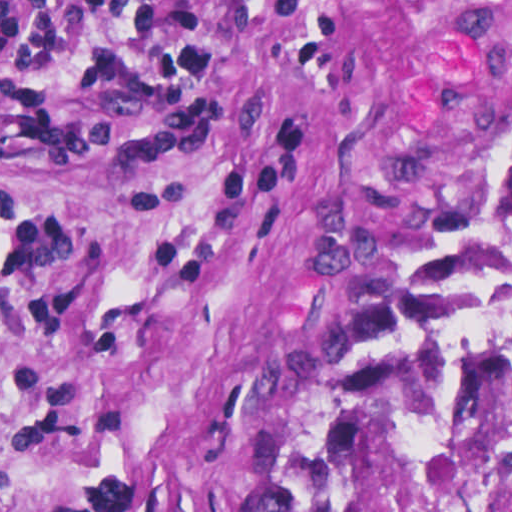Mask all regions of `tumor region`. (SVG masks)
<instances>
[{
    "mask_svg": "<svg viewBox=\"0 0 512 512\" xmlns=\"http://www.w3.org/2000/svg\"><path fill=\"white\" fill-rule=\"evenodd\" d=\"M511 166L512 35L460 73L445 104L432 177L338 356L303 512H340L428 298Z\"/></svg>",
    "mask_w": 512,
    "mask_h": 512,
    "instance_id": "tumor-region-1",
    "label": "tumor region"
}]
</instances>
